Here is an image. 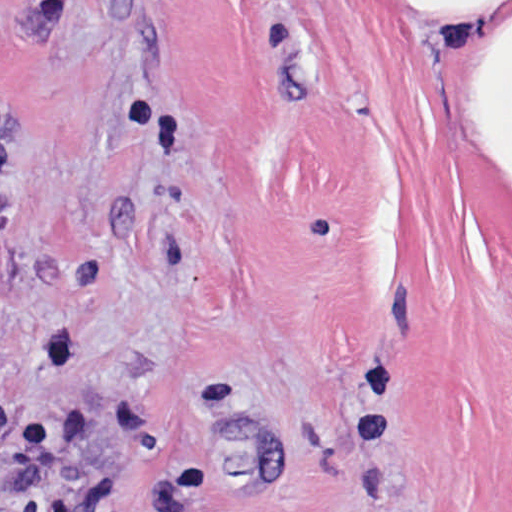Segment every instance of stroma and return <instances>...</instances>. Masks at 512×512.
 Listing matches in <instances>:
<instances>
[{"mask_svg":"<svg viewBox=\"0 0 512 512\" xmlns=\"http://www.w3.org/2000/svg\"><path fill=\"white\" fill-rule=\"evenodd\" d=\"M0 512H512V0H0Z\"/></svg>","mask_w":512,"mask_h":512,"instance_id":"35a3bbf8","label":"stroma"}]
</instances>
